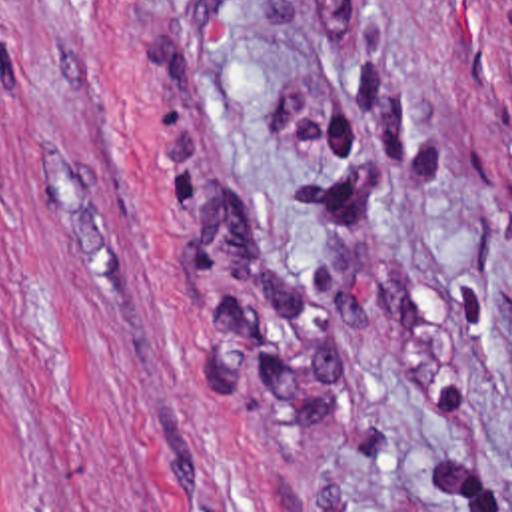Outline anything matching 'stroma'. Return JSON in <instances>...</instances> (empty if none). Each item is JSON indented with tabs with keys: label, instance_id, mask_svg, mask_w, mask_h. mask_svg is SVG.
I'll use <instances>...</instances> for the list:
<instances>
[{
	"label": "stroma",
	"instance_id": "stroma-1",
	"mask_svg": "<svg viewBox=\"0 0 512 512\" xmlns=\"http://www.w3.org/2000/svg\"><path fill=\"white\" fill-rule=\"evenodd\" d=\"M0 512H512L486 0H0Z\"/></svg>",
	"mask_w": 512,
	"mask_h": 512
}]
</instances>
